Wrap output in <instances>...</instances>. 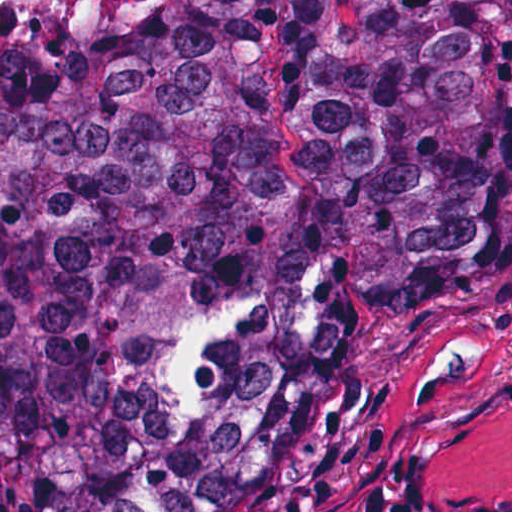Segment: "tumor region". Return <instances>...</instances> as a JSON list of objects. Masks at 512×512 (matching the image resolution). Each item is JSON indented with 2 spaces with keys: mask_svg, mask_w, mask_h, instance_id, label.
<instances>
[{
  "mask_svg": "<svg viewBox=\"0 0 512 512\" xmlns=\"http://www.w3.org/2000/svg\"><path fill=\"white\" fill-rule=\"evenodd\" d=\"M511 224L512 0H0V512H257Z\"/></svg>",
  "mask_w": 512,
  "mask_h": 512,
  "instance_id": "e687c5a6",
  "label": "tumor region"
}]
</instances>
